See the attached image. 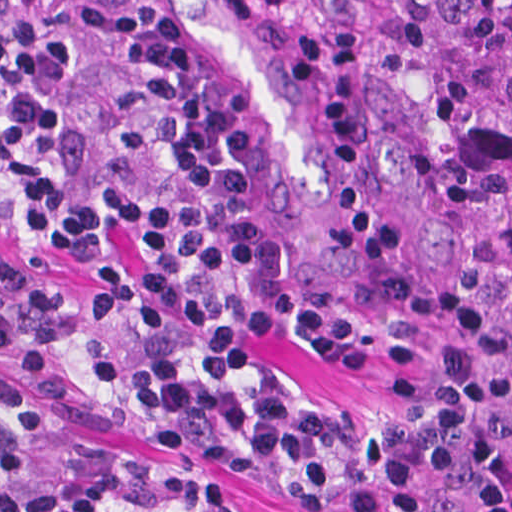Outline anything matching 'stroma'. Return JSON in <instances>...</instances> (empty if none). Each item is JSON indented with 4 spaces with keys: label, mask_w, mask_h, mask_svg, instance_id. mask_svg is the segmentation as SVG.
Returning a JSON list of instances; mask_svg holds the SVG:
<instances>
[{
    "label": "stroma",
    "mask_w": 512,
    "mask_h": 512,
    "mask_svg": "<svg viewBox=\"0 0 512 512\" xmlns=\"http://www.w3.org/2000/svg\"><path fill=\"white\" fill-rule=\"evenodd\" d=\"M201 44L214 93L238 114L258 165L261 207L290 251L339 293L405 284L465 294L496 332L512 370V320L479 286L485 229L439 115L350 40V0H159ZM0 261L55 283H91L31 239L0 235ZM261 360L312 406L347 421L384 407L396 363L362 374L259 343ZM0 386L47 423L120 461L203 473L244 512H290L276 490L236 471L161 453L54 406L0 350Z\"/></svg>",
    "instance_id": "35a3bbf8"
}]
</instances>
